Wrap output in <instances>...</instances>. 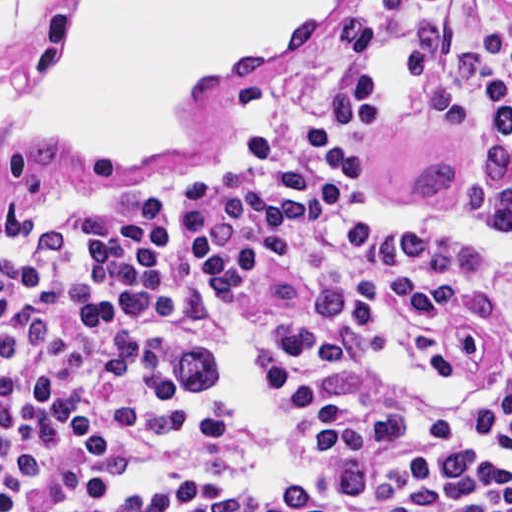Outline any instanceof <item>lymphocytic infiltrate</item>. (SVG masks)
Listing matches in <instances>:
<instances>
[{"mask_svg": "<svg viewBox=\"0 0 512 512\" xmlns=\"http://www.w3.org/2000/svg\"><path fill=\"white\" fill-rule=\"evenodd\" d=\"M0 512H512V30L2 247Z\"/></svg>", "mask_w": 512, "mask_h": 512, "instance_id": "1", "label": "lymphocytic infiltrate"}]
</instances>
